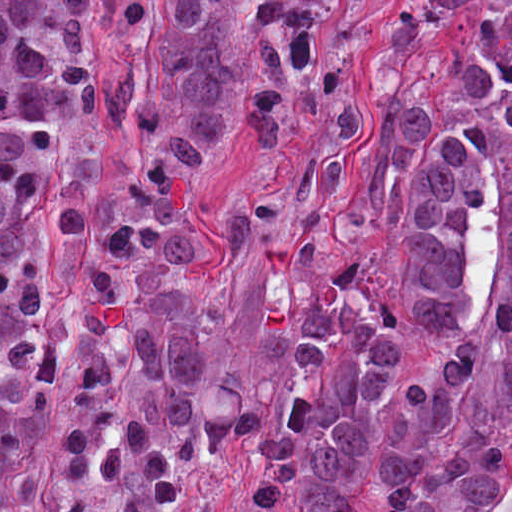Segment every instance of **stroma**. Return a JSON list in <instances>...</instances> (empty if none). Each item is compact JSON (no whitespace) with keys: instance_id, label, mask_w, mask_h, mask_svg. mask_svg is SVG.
<instances>
[{"instance_id":"obj_1","label":"stroma","mask_w":512,"mask_h":512,"mask_svg":"<svg viewBox=\"0 0 512 512\" xmlns=\"http://www.w3.org/2000/svg\"><path fill=\"white\" fill-rule=\"evenodd\" d=\"M405 0H340L332 38L334 76L357 97L361 131L343 159V180L325 235V256L370 278L347 244L344 207L360 160L378 126L375 90L368 76L383 28ZM142 20L123 26L110 0H93L92 21L111 52L98 86L94 114L71 130L56 148L53 167L83 218L79 241L56 239L52 205L44 193L34 208V240L57 303L54 330L60 344L54 395L29 453L36 467L19 512H52L74 454L78 383L73 363L80 351L76 321L93 277L105 236L129 194L131 150L122 135L106 126V114L129 85L149 90L163 61L166 0H143ZM259 150L246 122L233 112L207 153L195 181L190 216L194 245L187 259L188 311L209 332L204 413L213 419L229 411L244 414L264 396L270 375L257 338L262 270L249 254L225 267L224 242L235 206L252 186ZM402 350L385 392L380 421L393 396L409 384L424 357L418 337L400 319ZM512 456V420L500 432ZM251 487V470L241 459L207 468L189 490L184 512H240Z\"/></svg>"}]
</instances>
